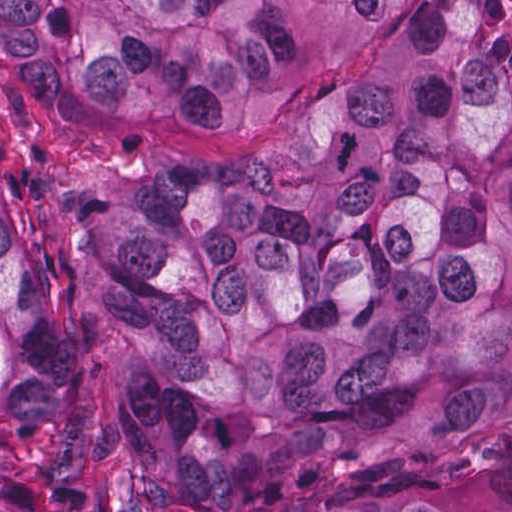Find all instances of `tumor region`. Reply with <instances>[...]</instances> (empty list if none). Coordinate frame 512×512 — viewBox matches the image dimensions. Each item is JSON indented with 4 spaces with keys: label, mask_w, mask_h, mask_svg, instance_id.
<instances>
[{
    "label": "tumor region",
    "mask_w": 512,
    "mask_h": 512,
    "mask_svg": "<svg viewBox=\"0 0 512 512\" xmlns=\"http://www.w3.org/2000/svg\"><path fill=\"white\" fill-rule=\"evenodd\" d=\"M217 165L46 180L125 340L128 512H512V41L495 1H1L74 121L264 122ZM98 431L1 163V512H64Z\"/></svg>",
    "instance_id": "tumor-region-1"
}]
</instances>
